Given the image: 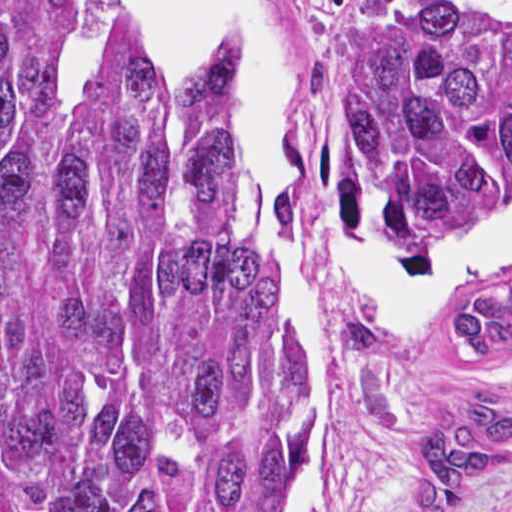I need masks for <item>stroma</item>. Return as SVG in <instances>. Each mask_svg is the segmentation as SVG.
<instances>
[{"label":"stroma","instance_id":"stroma-1","mask_svg":"<svg viewBox=\"0 0 512 512\" xmlns=\"http://www.w3.org/2000/svg\"><path fill=\"white\" fill-rule=\"evenodd\" d=\"M274 2L302 68L299 177L334 205L381 223L370 170L335 118L332 75L349 26L400 0ZM290 234L304 268L323 382L305 512H408L437 434L473 414L492 379L512 394V340L497 342L490 357H477L450 326L472 292L468 301L512 279V271L461 291L403 334L377 330L374 348L363 349L346 335L359 316L291 225ZM442 243L498 250L512 246V229ZM458 512H512V452L485 472Z\"/></svg>","mask_w":512,"mask_h":512}]
</instances>
